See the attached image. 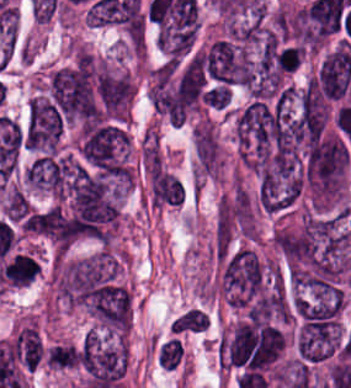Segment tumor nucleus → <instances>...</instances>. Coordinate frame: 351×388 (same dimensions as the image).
I'll return each mask as SVG.
<instances>
[{
    "label": "tumor nucleus",
    "mask_w": 351,
    "mask_h": 388,
    "mask_svg": "<svg viewBox=\"0 0 351 388\" xmlns=\"http://www.w3.org/2000/svg\"><path fill=\"white\" fill-rule=\"evenodd\" d=\"M76 142L81 162L92 171L111 179L132 180L129 140L122 124L81 122Z\"/></svg>",
    "instance_id": "tumor-nucleus-1"
},
{
    "label": "tumor nucleus",
    "mask_w": 351,
    "mask_h": 388,
    "mask_svg": "<svg viewBox=\"0 0 351 388\" xmlns=\"http://www.w3.org/2000/svg\"><path fill=\"white\" fill-rule=\"evenodd\" d=\"M81 387L121 382L127 363L125 339L119 333L89 328L75 348Z\"/></svg>",
    "instance_id": "tumor-nucleus-2"
},
{
    "label": "tumor nucleus",
    "mask_w": 351,
    "mask_h": 388,
    "mask_svg": "<svg viewBox=\"0 0 351 388\" xmlns=\"http://www.w3.org/2000/svg\"><path fill=\"white\" fill-rule=\"evenodd\" d=\"M149 197L152 206H179L183 189L175 175L161 169L149 174Z\"/></svg>",
    "instance_id": "tumor-nucleus-3"
},
{
    "label": "tumor nucleus",
    "mask_w": 351,
    "mask_h": 388,
    "mask_svg": "<svg viewBox=\"0 0 351 388\" xmlns=\"http://www.w3.org/2000/svg\"><path fill=\"white\" fill-rule=\"evenodd\" d=\"M208 320L200 307L189 306L175 315L169 323V332L177 335L202 333Z\"/></svg>",
    "instance_id": "tumor-nucleus-4"
},
{
    "label": "tumor nucleus",
    "mask_w": 351,
    "mask_h": 388,
    "mask_svg": "<svg viewBox=\"0 0 351 388\" xmlns=\"http://www.w3.org/2000/svg\"><path fill=\"white\" fill-rule=\"evenodd\" d=\"M44 365L54 371L75 369L76 360L71 342H59L47 346Z\"/></svg>",
    "instance_id": "tumor-nucleus-5"
},
{
    "label": "tumor nucleus",
    "mask_w": 351,
    "mask_h": 388,
    "mask_svg": "<svg viewBox=\"0 0 351 388\" xmlns=\"http://www.w3.org/2000/svg\"><path fill=\"white\" fill-rule=\"evenodd\" d=\"M182 354V343L179 337L166 339L158 355L159 364L163 368L176 369Z\"/></svg>",
    "instance_id": "tumor-nucleus-6"
},
{
    "label": "tumor nucleus",
    "mask_w": 351,
    "mask_h": 388,
    "mask_svg": "<svg viewBox=\"0 0 351 388\" xmlns=\"http://www.w3.org/2000/svg\"><path fill=\"white\" fill-rule=\"evenodd\" d=\"M228 99L229 88L224 84H217L201 95V101L215 110H222Z\"/></svg>",
    "instance_id": "tumor-nucleus-7"
}]
</instances>
